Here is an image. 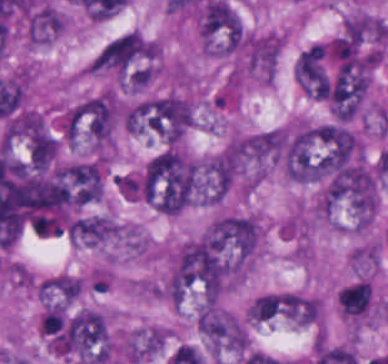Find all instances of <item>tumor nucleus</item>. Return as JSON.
I'll return each mask as SVG.
<instances>
[{
    "label": "tumor nucleus",
    "instance_id": "1",
    "mask_svg": "<svg viewBox=\"0 0 388 364\" xmlns=\"http://www.w3.org/2000/svg\"><path fill=\"white\" fill-rule=\"evenodd\" d=\"M202 184L196 164L176 146L150 158L139 177V197L154 211L175 216L197 202Z\"/></svg>",
    "mask_w": 388,
    "mask_h": 364
},
{
    "label": "tumor nucleus",
    "instance_id": "3",
    "mask_svg": "<svg viewBox=\"0 0 388 364\" xmlns=\"http://www.w3.org/2000/svg\"><path fill=\"white\" fill-rule=\"evenodd\" d=\"M114 220L108 216H82L70 223V241L85 247H96L119 233Z\"/></svg>",
    "mask_w": 388,
    "mask_h": 364
},
{
    "label": "tumor nucleus",
    "instance_id": "2",
    "mask_svg": "<svg viewBox=\"0 0 388 364\" xmlns=\"http://www.w3.org/2000/svg\"><path fill=\"white\" fill-rule=\"evenodd\" d=\"M196 322L213 355H224L247 348L245 331L232 312L218 306L204 305L198 311Z\"/></svg>",
    "mask_w": 388,
    "mask_h": 364
}]
</instances>
